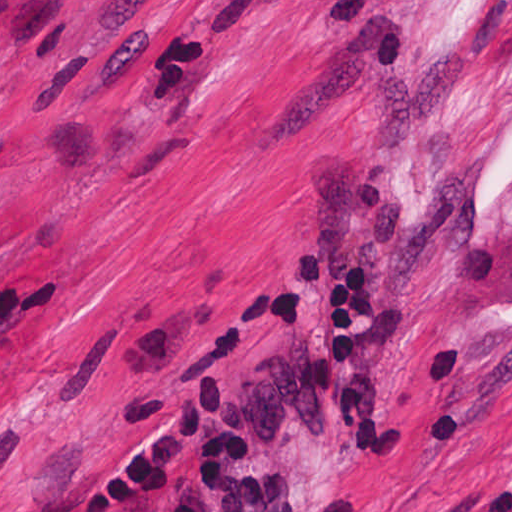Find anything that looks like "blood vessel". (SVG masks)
<instances>
[{
  "label": "blood vessel",
  "mask_w": 512,
  "mask_h": 512,
  "mask_svg": "<svg viewBox=\"0 0 512 512\" xmlns=\"http://www.w3.org/2000/svg\"><path fill=\"white\" fill-rule=\"evenodd\" d=\"M0 512H92L86 505L52 500H16Z\"/></svg>",
  "instance_id": "8fb6f2fc"
}]
</instances>
